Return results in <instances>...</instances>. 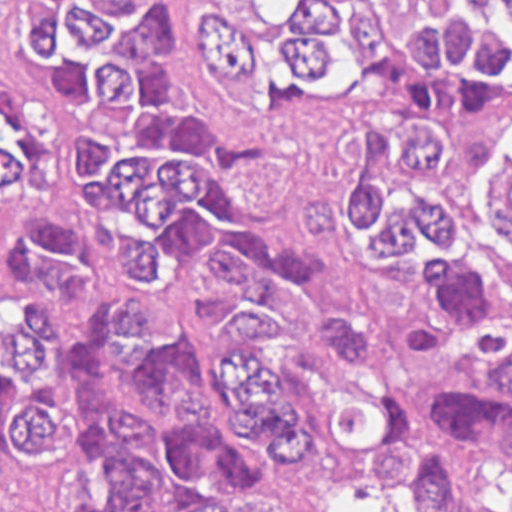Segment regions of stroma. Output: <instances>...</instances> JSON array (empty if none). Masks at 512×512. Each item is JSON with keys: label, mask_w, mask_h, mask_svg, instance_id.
<instances>
[{"label": "stroma", "mask_w": 512, "mask_h": 512, "mask_svg": "<svg viewBox=\"0 0 512 512\" xmlns=\"http://www.w3.org/2000/svg\"><path fill=\"white\" fill-rule=\"evenodd\" d=\"M213 0H162L173 41L159 49L162 104L179 109L223 138H254L269 147L272 163L241 174L233 200L259 237L300 251L313 265L309 293L318 305L354 323L364 340L356 357L329 352L278 309L263 333H245L248 348L273 372L279 397L294 404L305 431H320L334 399L364 396L397 403L406 394L474 357L489 333L465 322L431 281L425 248L416 261L380 265L354 237L317 244L301 237V215L311 198L347 195L366 164L370 126L410 129L423 122L443 133V168L425 175V192L458 212L475 248L490 260H511L512 241L493 213L490 174L512 161V108L489 115H436L382 84L350 88L307 113L254 110L222 97L203 70L200 19ZM47 88L22 32V0H0V512H1V109L33 113ZM129 104L72 90L56 93L42 120L36 198L73 231L83 290L61 318L48 349V384L66 434L57 457L32 482L20 512H54L59 477L91 451L88 416L74 390V369L100 311L140 292L74 149L81 135L109 127ZM457 468L455 512H512V457L437 446ZM391 494L403 506L399 496ZM159 507H106L104 512H162ZM368 499L338 497L323 512H366Z\"/></svg>", "instance_id": "stroma-1"}]
</instances>
